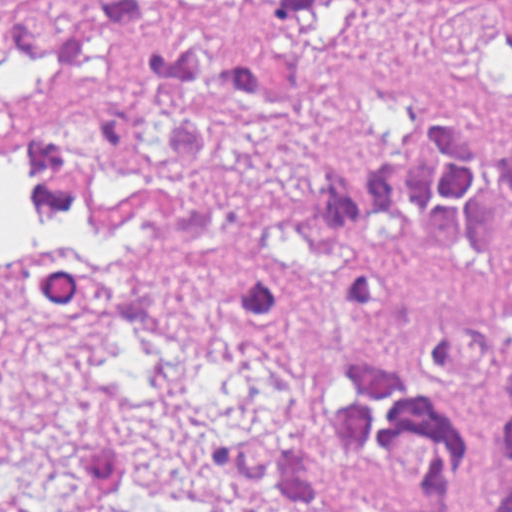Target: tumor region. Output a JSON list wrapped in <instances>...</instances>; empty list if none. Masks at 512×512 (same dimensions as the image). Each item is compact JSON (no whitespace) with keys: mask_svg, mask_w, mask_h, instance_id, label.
<instances>
[{"mask_svg":"<svg viewBox=\"0 0 512 512\" xmlns=\"http://www.w3.org/2000/svg\"><path fill=\"white\" fill-rule=\"evenodd\" d=\"M360 0H0V225L47 313L80 324H251L342 268L350 335L291 373L275 420L213 436L210 467L265 512H477L483 413L512 374V138L402 123L259 215L217 197L284 109L263 21ZM512 512V402L491 415ZM53 512H202L170 460L74 440Z\"/></svg>","mask_w":512,"mask_h":512,"instance_id":"obj_1","label":"tumor region"}]
</instances>
